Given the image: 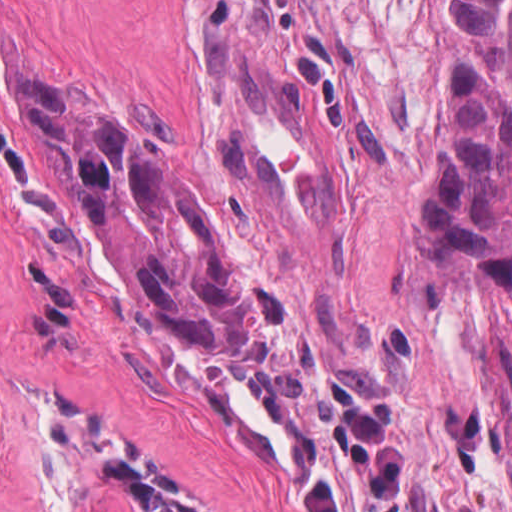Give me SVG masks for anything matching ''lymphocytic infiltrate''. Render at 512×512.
<instances>
[{"mask_svg": "<svg viewBox=\"0 0 512 512\" xmlns=\"http://www.w3.org/2000/svg\"><path fill=\"white\" fill-rule=\"evenodd\" d=\"M331 459L352 470L364 512H403V460L392 440L394 409L370 403L329 382L314 393ZM103 476L124 492L137 512H197L182 485L146 470L133 454L109 455ZM300 512H344L330 480L304 475L291 491Z\"/></svg>", "mask_w": 512, "mask_h": 512, "instance_id": "f902f5d3", "label": "lymphocytic infiltrate"}]
</instances>
